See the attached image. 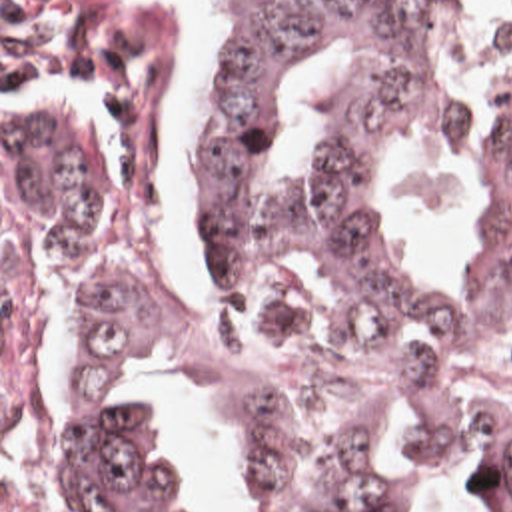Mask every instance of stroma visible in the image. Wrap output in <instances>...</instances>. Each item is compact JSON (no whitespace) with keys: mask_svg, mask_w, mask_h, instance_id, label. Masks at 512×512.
Instances as JSON below:
<instances>
[{"mask_svg":"<svg viewBox=\"0 0 512 512\" xmlns=\"http://www.w3.org/2000/svg\"><path fill=\"white\" fill-rule=\"evenodd\" d=\"M166 68L176 216L168 232L132 248H32L2 198V0H0V512L2 467L54 457L68 415V332L62 264H106L168 308L248 354L276 395L296 407L335 409L367 387L431 385L512 413V374L387 375L343 362L325 344L292 342L236 302L202 262L196 228V110L220 26L198 0H136ZM512 0H453V12Z\"/></svg>","mask_w":512,"mask_h":512,"instance_id":"obj_1","label":"stroma"}]
</instances>
